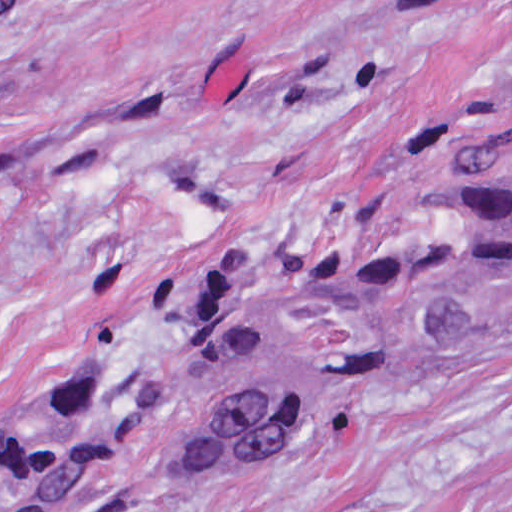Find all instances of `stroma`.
I'll return each instance as SVG.
<instances>
[{"instance_id": "stroma-1", "label": "stroma", "mask_w": 512, "mask_h": 512, "mask_svg": "<svg viewBox=\"0 0 512 512\" xmlns=\"http://www.w3.org/2000/svg\"><path fill=\"white\" fill-rule=\"evenodd\" d=\"M510 114L512 0H0V444L99 341L86 512H511L512 324L247 472L173 410L205 265Z\"/></svg>"}]
</instances>
